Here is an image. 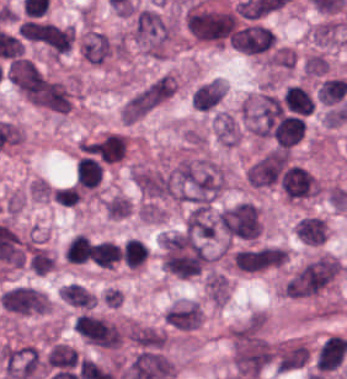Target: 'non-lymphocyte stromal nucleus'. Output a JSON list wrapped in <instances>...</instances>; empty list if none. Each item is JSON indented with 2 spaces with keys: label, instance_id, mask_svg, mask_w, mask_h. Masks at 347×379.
I'll return each mask as SVG.
<instances>
[{
  "label": "non-lymphocyte stromal nucleus",
  "instance_id": "dd21d789",
  "mask_svg": "<svg viewBox=\"0 0 347 379\" xmlns=\"http://www.w3.org/2000/svg\"><path fill=\"white\" fill-rule=\"evenodd\" d=\"M10 80L28 103L55 116L66 115L73 106L76 88L37 63L14 59Z\"/></svg>",
  "mask_w": 347,
  "mask_h": 379
},
{
  "label": "non-lymphocyte stromal nucleus",
  "instance_id": "a72fc3eb",
  "mask_svg": "<svg viewBox=\"0 0 347 379\" xmlns=\"http://www.w3.org/2000/svg\"><path fill=\"white\" fill-rule=\"evenodd\" d=\"M176 201L211 206L226 185L225 165L210 158H184L171 169Z\"/></svg>",
  "mask_w": 347,
  "mask_h": 379
},
{
  "label": "non-lymphocyte stromal nucleus",
  "instance_id": "3746e769",
  "mask_svg": "<svg viewBox=\"0 0 347 379\" xmlns=\"http://www.w3.org/2000/svg\"><path fill=\"white\" fill-rule=\"evenodd\" d=\"M273 356V345L262 312H254L231 331V363L244 379L265 371Z\"/></svg>",
  "mask_w": 347,
  "mask_h": 379
},
{
  "label": "non-lymphocyte stromal nucleus",
  "instance_id": "fc2b8d12",
  "mask_svg": "<svg viewBox=\"0 0 347 379\" xmlns=\"http://www.w3.org/2000/svg\"><path fill=\"white\" fill-rule=\"evenodd\" d=\"M240 19L235 8L198 1L185 15L184 25L193 40L231 46Z\"/></svg>",
  "mask_w": 347,
  "mask_h": 379
},
{
  "label": "non-lymphocyte stromal nucleus",
  "instance_id": "81446118",
  "mask_svg": "<svg viewBox=\"0 0 347 379\" xmlns=\"http://www.w3.org/2000/svg\"><path fill=\"white\" fill-rule=\"evenodd\" d=\"M338 258L319 254L296 270L283 285L284 295L299 299L325 289L341 269Z\"/></svg>",
  "mask_w": 347,
  "mask_h": 379
},
{
  "label": "non-lymphocyte stromal nucleus",
  "instance_id": "7c5642bf",
  "mask_svg": "<svg viewBox=\"0 0 347 379\" xmlns=\"http://www.w3.org/2000/svg\"><path fill=\"white\" fill-rule=\"evenodd\" d=\"M132 37L147 55L162 58L170 38V24L152 8L141 7L134 16Z\"/></svg>",
  "mask_w": 347,
  "mask_h": 379
},
{
  "label": "non-lymphocyte stromal nucleus",
  "instance_id": "9d01c50a",
  "mask_svg": "<svg viewBox=\"0 0 347 379\" xmlns=\"http://www.w3.org/2000/svg\"><path fill=\"white\" fill-rule=\"evenodd\" d=\"M223 234L238 241H251L263 231V219L254 201H241L219 213Z\"/></svg>",
  "mask_w": 347,
  "mask_h": 379
},
{
  "label": "non-lymphocyte stromal nucleus",
  "instance_id": "2ac0efb1",
  "mask_svg": "<svg viewBox=\"0 0 347 379\" xmlns=\"http://www.w3.org/2000/svg\"><path fill=\"white\" fill-rule=\"evenodd\" d=\"M132 176L141 195L151 200L173 198L175 178L170 169L135 167Z\"/></svg>",
  "mask_w": 347,
  "mask_h": 379
},
{
  "label": "non-lymphocyte stromal nucleus",
  "instance_id": "616ff342",
  "mask_svg": "<svg viewBox=\"0 0 347 379\" xmlns=\"http://www.w3.org/2000/svg\"><path fill=\"white\" fill-rule=\"evenodd\" d=\"M226 90V84L220 78L203 82L192 94L193 108L199 113H212L219 108Z\"/></svg>",
  "mask_w": 347,
  "mask_h": 379
},
{
  "label": "non-lymphocyte stromal nucleus",
  "instance_id": "6412c185",
  "mask_svg": "<svg viewBox=\"0 0 347 379\" xmlns=\"http://www.w3.org/2000/svg\"><path fill=\"white\" fill-rule=\"evenodd\" d=\"M215 136L227 146H235L242 138L241 120L227 110H220L214 122Z\"/></svg>",
  "mask_w": 347,
  "mask_h": 379
},
{
  "label": "non-lymphocyte stromal nucleus",
  "instance_id": "0ceb972a",
  "mask_svg": "<svg viewBox=\"0 0 347 379\" xmlns=\"http://www.w3.org/2000/svg\"><path fill=\"white\" fill-rule=\"evenodd\" d=\"M342 36L343 24L333 19H326L317 24L311 33L314 45L321 48H331Z\"/></svg>",
  "mask_w": 347,
  "mask_h": 379
},
{
  "label": "non-lymphocyte stromal nucleus",
  "instance_id": "51effc4e",
  "mask_svg": "<svg viewBox=\"0 0 347 379\" xmlns=\"http://www.w3.org/2000/svg\"><path fill=\"white\" fill-rule=\"evenodd\" d=\"M300 68L306 77L325 78L329 71V64L326 56L311 52L301 60Z\"/></svg>",
  "mask_w": 347,
  "mask_h": 379
},
{
  "label": "non-lymphocyte stromal nucleus",
  "instance_id": "bbfbcbc0",
  "mask_svg": "<svg viewBox=\"0 0 347 379\" xmlns=\"http://www.w3.org/2000/svg\"><path fill=\"white\" fill-rule=\"evenodd\" d=\"M105 214L110 220H124L130 216L132 203L129 197L114 194L104 203Z\"/></svg>",
  "mask_w": 347,
  "mask_h": 379
}]
</instances>
